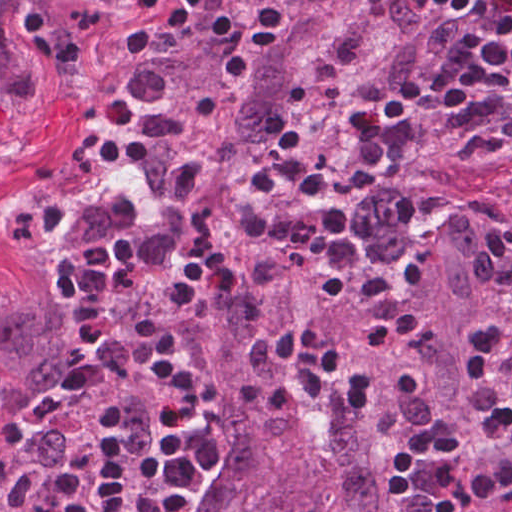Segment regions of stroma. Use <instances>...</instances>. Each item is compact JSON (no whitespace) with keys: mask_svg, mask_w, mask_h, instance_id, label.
<instances>
[{"mask_svg":"<svg viewBox=\"0 0 512 512\" xmlns=\"http://www.w3.org/2000/svg\"><path fill=\"white\" fill-rule=\"evenodd\" d=\"M161 39L137 21L0 173V288L33 269L84 204L123 182L139 195L131 180L140 139L137 126ZM477 199L500 213L501 230L512 224L511 186L484 182L456 203ZM494 290L495 286L490 307ZM176 351L180 361L193 371L202 397L196 416L179 430L190 429L200 435L207 457L208 415L202 361L192 351ZM124 370L146 405V448L135 449L127 441L130 456L119 512H159L154 457L171 404L149 354L138 362L124 364ZM101 372L97 386L68 390L71 392L36 416L25 406L21 409L19 422L26 437L37 441L57 430L66 434V448L39 484L27 512H52L65 504L79 512L91 488L87 461L104 431L122 427L126 437L123 408L117 403L83 408L67 433L53 419L60 407L112 385V367ZM9 391L0 368V437ZM451 427L459 438L458 450L465 471L488 458L465 432L456 412ZM204 481L205 472L186 512H193L202 500ZM435 489L434 484L431 504Z\"/></svg>","mask_w":512,"mask_h":512,"instance_id":"35a3bbf8","label":"stroma"}]
</instances>
